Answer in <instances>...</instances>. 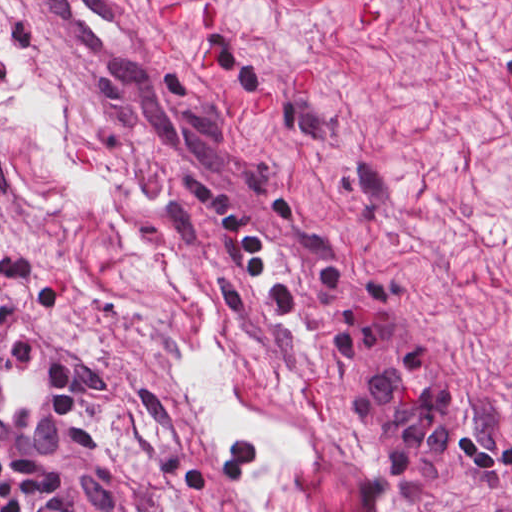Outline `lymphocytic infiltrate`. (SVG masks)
I'll return each instance as SVG.
<instances>
[{
    "label": "lymphocytic infiltrate",
    "mask_w": 512,
    "mask_h": 512,
    "mask_svg": "<svg viewBox=\"0 0 512 512\" xmlns=\"http://www.w3.org/2000/svg\"><path fill=\"white\" fill-rule=\"evenodd\" d=\"M27 324L45 325L67 348L75 420L66 437L43 454L0 449V512H139L111 471L100 408L52 308L0 272V340Z\"/></svg>",
    "instance_id": "f902f5d3"
}]
</instances>
